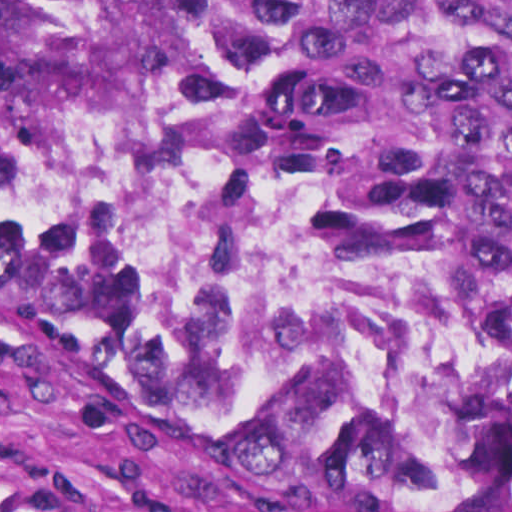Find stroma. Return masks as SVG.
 I'll use <instances>...</instances> for the list:
<instances>
[{
    "mask_svg": "<svg viewBox=\"0 0 512 512\" xmlns=\"http://www.w3.org/2000/svg\"><path fill=\"white\" fill-rule=\"evenodd\" d=\"M194 103L253 137L233 106ZM0 512H512L308 459L173 396L0 278Z\"/></svg>",
    "mask_w": 512,
    "mask_h": 512,
    "instance_id": "obj_1",
    "label": "stroma"
}]
</instances>
